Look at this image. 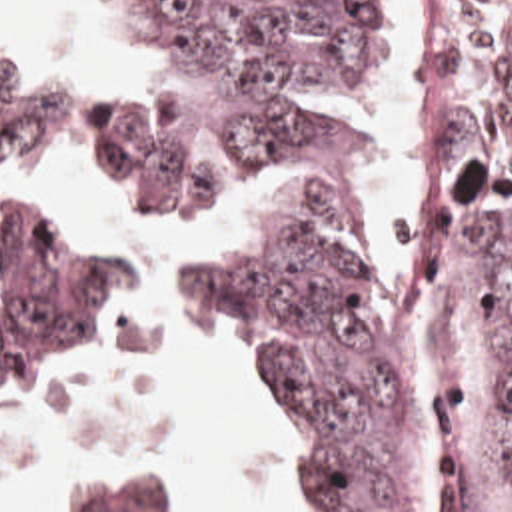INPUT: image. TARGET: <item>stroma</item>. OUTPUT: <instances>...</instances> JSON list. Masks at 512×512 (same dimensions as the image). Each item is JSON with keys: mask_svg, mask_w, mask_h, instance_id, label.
<instances>
[{"mask_svg": "<svg viewBox=\"0 0 512 512\" xmlns=\"http://www.w3.org/2000/svg\"><path fill=\"white\" fill-rule=\"evenodd\" d=\"M0 20L8 32V36L12 38V42L20 48V52L24 54L28 66L32 72H50L62 100H64V106H62V114H60V142L56 144V148L50 152V156L46 158L44 162V170H42V186L48 190L50 196L66 202L68 206L84 212L94 228V232L108 244L106 236L98 230V224H96V218L92 214L90 208L82 206L78 200H74L70 194L50 186V180H48V170H50V162L54 158V154H76L78 162H80V168L84 172V180H86V186L88 190L96 196V200L102 204L104 210L120 216L124 222H128L132 228H136L138 232H144V234H176L180 230H186V228H168V226H160V224H150V222H142V220H134V218H128L124 214H120L102 194L100 190L96 188V184L92 182L90 174H88V168H86V162H84V130H86V118H88V106H90V100L94 98H100V96H106V94H112L124 86H130V84H136V82H142L144 76H142V68H140V62H136L134 58H130L128 54H124L122 50L110 46L108 42L100 40L96 34H92L88 28H84L80 22H76L72 18V0H66V22H68V28L74 36V40L88 52H92L94 56L110 62L112 66L118 68L122 80H116V82H92V84H78L74 80H68L64 76H60L58 72H54L52 68L44 66V64H38L34 60L28 58L26 50L22 48L20 40H18V32H16V22L12 18V10H10V1L0 0ZM212 218H224L232 224L236 236L214 250V254L206 260H200V262H186V268L188 266H196V264H202V262H232L234 254L238 252L240 248V224L232 222L226 206L222 204L220 208H216L214 212H210L198 226H208V222ZM110 246V244H108ZM114 252V250H112ZM116 254V252H114ZM116 258L120 260L122 268H124V276H126V284H128V338H126V350H124V356L120 358H114V360H108L104 364H100L96 370H92L88 376H84L82 380L66 386V388H56V390H42V392H0V402H52V400H60L64 396H70L74 392H80V390H86V388H94V386H100L104 384L108 378H112L116 372H120L126 364H130L134 358H138L140 354H146V352H152L156 348H160L156 336L144 326V322L140 320V314H138V284L134 280V276L130 274L128 266L122 262V258L116 254ZM190 302L196 310H200L204 316H208L210 320L222 324L220 320H216L212 314H208L204 308H200L196 304V300L192 298L190 294ZM394 304L396 300H392L388 294H384L380 288H378V332H380V340H382V354H384V362L386 366L390 368V372L394 374V368H392V352H394ZM224 326V324H222ZM228 328V326H224ZM230 330V328H228ZM232 332V330H230ZM234 334V332H232ZM238 340V338H236ZM240 342V340H238ZM242 344V342H240ZM244 348V344H242ZM246 350V348H244ZM248 354V350H246ZM250 360V356H248ZM252 366V364H250ZM396 378V374H394ZM398 382V380H396ZM256 386V382H254ZM400 388V384H398ZM400 394L404 398V402L408 404V408L412 410V414L416 416L432 452H434V460H436V468H438V480H436V492H434V500H432V506H430V512H506L492 496L490 492L480 484V480L456 458L454 450L450 448L448 440L444 438L442 430L438 428L436 420L426 412V410H420L416 406H412L408 402V398L404 396L402 388H400ZM260 406H262V412H264V418L268 422V428L272 432V438L286 462V470H288V482H290V512H304V502H302V496H300V490H298V482H296V470H294V460H292V452H290V442H288V434H286V428L268 412V408L262 404L260 400ZM90 472H158V474H164V476H170L176 480L190 512H202L200 506H198V500L194 496V492L190 490V486L186 484V478H184V472L164 460V458H158V456H84L80 460H76L62 476H60V484H58V512H68L70 510V502H72V496H74V490L76 486L90 474Z\"/></svg>", "mask_w": 512, "mask_h": 512, "instance_id": "1", "label": "stroma"}]
</instances>
